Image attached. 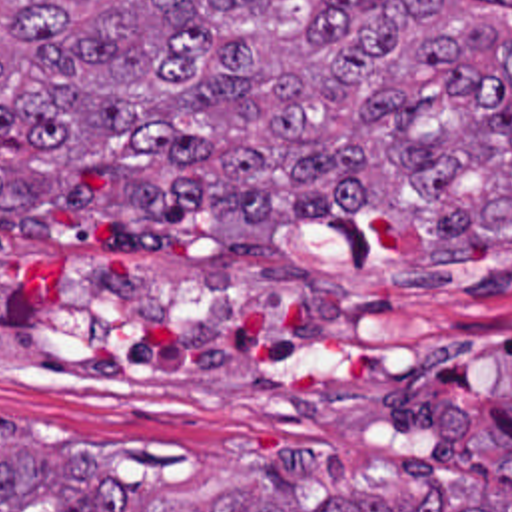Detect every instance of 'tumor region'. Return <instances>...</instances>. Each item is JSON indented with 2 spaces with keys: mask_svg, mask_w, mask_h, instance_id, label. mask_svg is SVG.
<instances>
[{
  "mask_svg": "<svg viewBox=\"0 0 512 512\" xmlns=\"http://www.w3.org/2000/svg\"><path fill=\"white\" fill-rule=\"evenodd\" d=\"M466 2L0 0V234L53 204L161 248L207 206L251 254L352 212L422 232V262L512 250V42ZM398 467L428 501L296 499V453L131 497L0 425V512H512Z\"/></svg>",
  "mask_w": 512,
  "mask_h": 512,
  "instance_id": "e687c5a6",
  "label": "tumor region"
}]
</instances>
